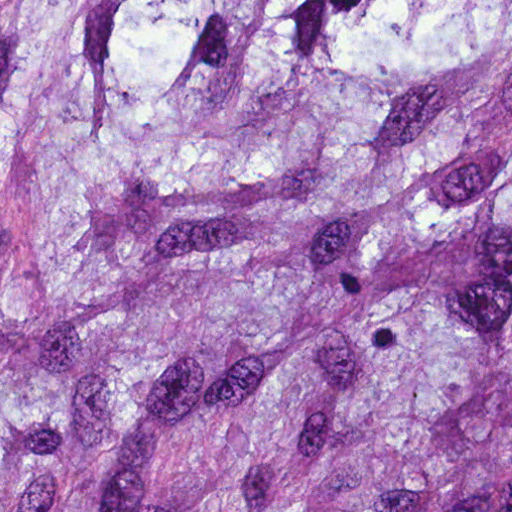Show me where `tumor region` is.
Masks as SVG:
<instances>
[{
	"instance_id": "tumor-region-1",
	"label": "tumor region",
	"mask_w": 512,
	"mask_h": 512,
	"mask_svg": "<svg viewBox=\"0 0 512 512\" xmlns=\"http://www.w3.org/2000/svg\"><path fill=\"white\" fill-rule=\"evenodd\" d=\"M0 512H512V0H0Z\"/></svg>"
}]
</instances>
